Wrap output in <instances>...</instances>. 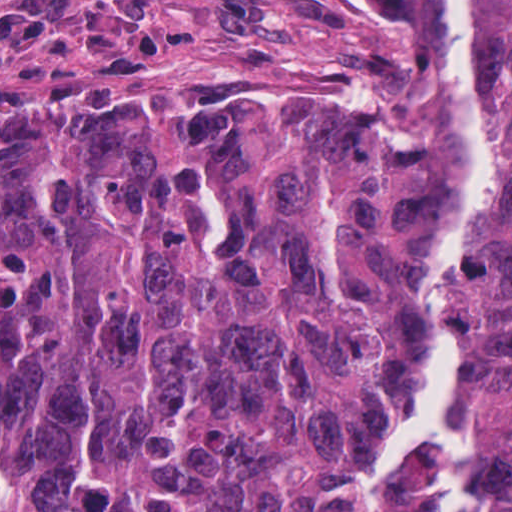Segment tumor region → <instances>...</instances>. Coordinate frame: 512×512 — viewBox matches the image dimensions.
<instances>
[{
    "mask_svg": "<svg viewBox=\"0 0 512 512\" xmlns=\"http://www.w3.org/2000/svg\"><path fill=\"white\" fill-rule=\"evenodd\" d=\"M269 1L309 33L0 97V512H430L437 449L375 470L434 366L458 123L512 204V0ZM440 4L435 41L399 14ZM444 303L512 512L509 228Z\"/></svg>",
    "mask_w": 512,
    "mask_h": 512,
    "instance_id": "e687c5a6",
    "label": "tumor region"
}]
</instances>
